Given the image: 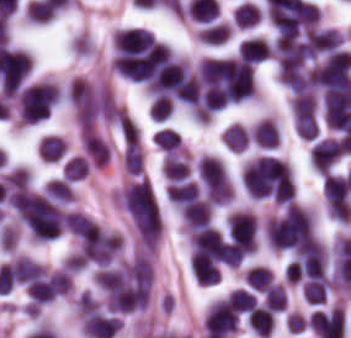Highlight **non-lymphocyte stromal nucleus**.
<instances>
[{
    "label": "non-lymphocyte stromal nucleus",
    "mask_w": 351,
    "mask_h": 338,
    "mask_svg": "<svg viewBox=\"0 0 351 338\" xmlns=\"http://www.w3.org/2000/svg\"><path fill=\"white\" fill-rule=\"evenodd\" d=\"M119 206L141 239L159 241L162 222L147 180L137 175L123 183Z\"/></svg>",
    "instance_id": "non-lymphocyte-stromal-nucleus-1"
}]
</instances>
